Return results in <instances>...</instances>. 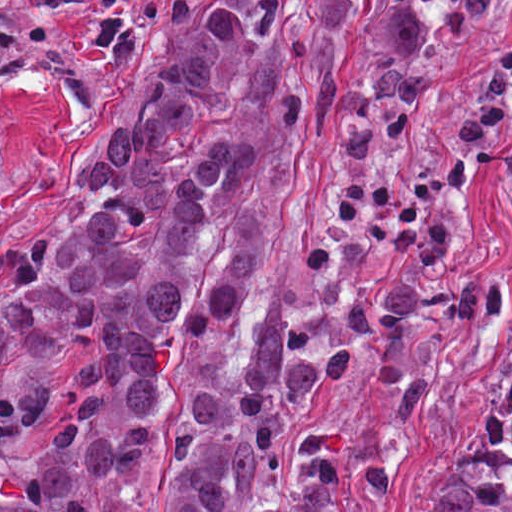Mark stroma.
Segmentation results:
<instances>
[{
	"label": "stroma",
	"instance_id": "stroma-1",
	"mask_svg": "<svg viewBox=\"0 0 512 512\" xmlns=\"http://www.w3.org/2000/svg\"><path fill=\"white\" fill-rule=\"evenodd\" d=\"M512 74V32L306 123L292 190L276 215V268L293 310H343L381 280L449 289L475 280L509 286L511 303L496 315L417 322L431 368L423 399H393L369 388H336L321 413L337 454H385L388 484L373 499L341 512H406L436 485L490 416L512 366V129L486 141L474 169L453 189L456 269L419 266L397 248L366 254L359 268L313 279L302 249L333 226L327 177L342 168H399L441 157L467 83L478 70ZM25 249V248H24ZM20 250L0 260V302L21 284ZM211 361L206 338L186 343L163 392L153 448L132 488L143 512H166L186 402ZM93 512H110L97 485Z\"/></svg>",
	"mask_w": 512,
	"mask_h": 512
}]
</instances>
